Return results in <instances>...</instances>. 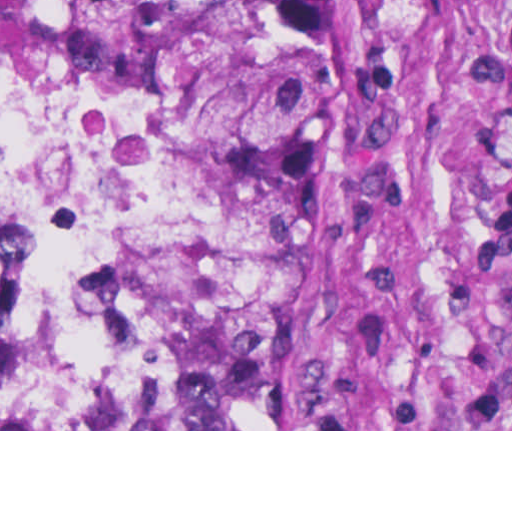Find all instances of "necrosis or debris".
I'll list each match as a JSON object with an SVG mask.
<instances>
[{
	"mask_svg": "<svg viewBox=\"0 0 512 512\" xmlns=\"http://www.w3.org/2000/svg\"><path fill=\"white\" fill-rule=\"evenodd\" d=\"M229 147L159 106L0 69V424L180 386L201 308L251 244ZM324 341V306L287 429Z\"/></svg>",
	"mask_w": 512,
	"mask_h": 512,
	"instance_id": "obj_1",
	"label": "necrosis or debris"
}]
</instances>
